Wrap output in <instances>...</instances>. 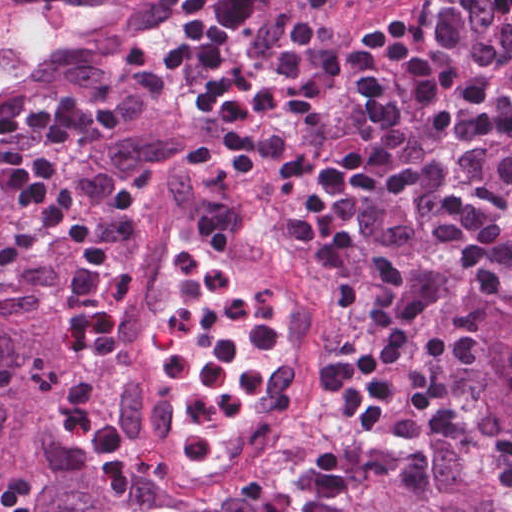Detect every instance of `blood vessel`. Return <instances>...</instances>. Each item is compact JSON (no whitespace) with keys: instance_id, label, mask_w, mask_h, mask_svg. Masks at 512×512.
<instances>
[{"instance_id":"8fb6f2fc","label":"blood vessel","mask_w":512,"mask_h":512,"mask_svg":"<svg viewBox=\"0 0 512 512\" xmlns=\"http://www.w3.org/2000/svg\"><path fill=\"white\" fill-rule=\"evenodd\" d=\"M168 1L0 0V109L148 27ZM349 1L369 12L391 0ZM123 234L135 238L137 264L122 334L112 351L100 354L97 391L125 427L150 430L168 416L150 365L145 321L167 291L169 254L189 240L268 284L277 300L297 314L307 339L276 363L268 388L282 406L311 418L322 390L319 362L335 361L340 335V314L330 292L317 281H303L308 276L254 232L183 194L152 196Z\"/></svg>"}]
</instances>
